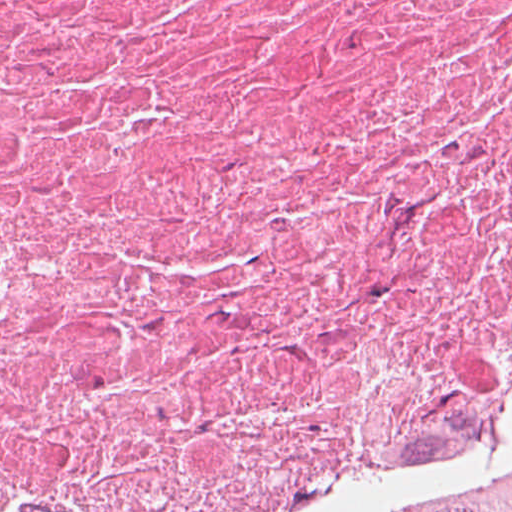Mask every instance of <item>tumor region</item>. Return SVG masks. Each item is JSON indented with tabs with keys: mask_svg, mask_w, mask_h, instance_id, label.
<instances>
[{
	"mask_svg": "<svg viewBox=\"0 0 512 512\" xmlns=\"http://www.w3.org/2000/svg\"><path fill=\"white\" fill-rule=\"evenodd\" d=\"M443 512H512V489L483 501Z\"/></svg>",
	"mask_w": 512,
	"mask_h": 512,
	"instance_id": "obj_1",
	"label": "tumor region"
}]
</instances>
